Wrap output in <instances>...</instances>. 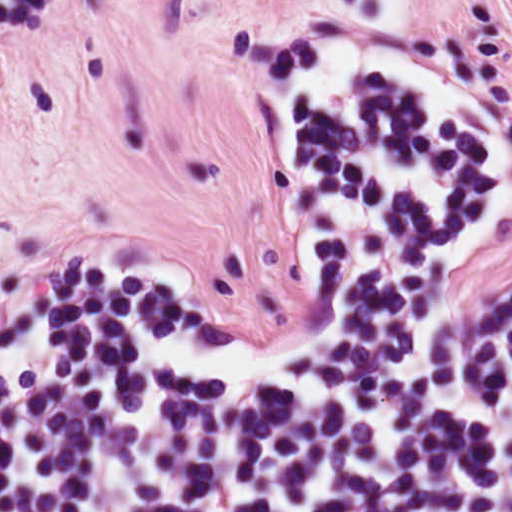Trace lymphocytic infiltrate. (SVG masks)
I'll return each instance as SVG.
<instances>
[{
	"mask_svg": "<svg viewBox=\"0 0 512 512\" xmlns=\"http://www.w3.org/2000/svg\"><path fill=\"white\" fill-rule=\"evenodd\" d=\"M303 309L274 336L123 253L32 275L0 336V512H512V116L387 56L299 95Z\"/></svg>",
	"mask_w": 512,
	"mask_h": 512,
	"instance_id": "obj_1",
	"label": "lymphocytic infiltrate"
}]
</instances>
